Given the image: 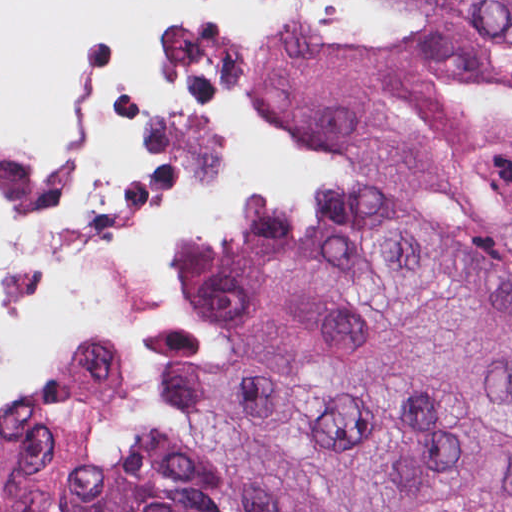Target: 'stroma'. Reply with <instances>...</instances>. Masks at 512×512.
Here are the masks:
<instances>
[{
  "mask_svg": "<svg viewBox=\"0 0 512 512\" xmlns=\"http://www.w3.org/2000/svg\"><path fill=\"white\" fill-rule=\"evenodd\" d=\"M410 33L408 13L390 5V26L380 39L337 45L383 48L399 45ZM257 88L261 103L288 126L266 99L260 80ZM295 133L307 142L322 178L306 191H275L262 196L296 201L317 211H334L344 192L342 168L323 145ZM230 215L212 230L193 240L220 236L229 225ZM142 331H161L174 336L197 362L214 365L219 349L214 329L173 295L171 303L157 317L142 325L139 332ZM72 356L75 355L68 351H51L37 362L13 393L2 394L11 401L33 400L51 387L65 359ZM135 359L142 372V395L138 410L120 416H104V440L118 453L138 448L153 432L167 435L170 432L172 394L159 375L147 368L136 355Z\"/></svg>",
  "mask_w": 512,
  "mask_h": 512,
  "instance_id": "stroma-1",
  "label": "stroma"
}]
</instances>
